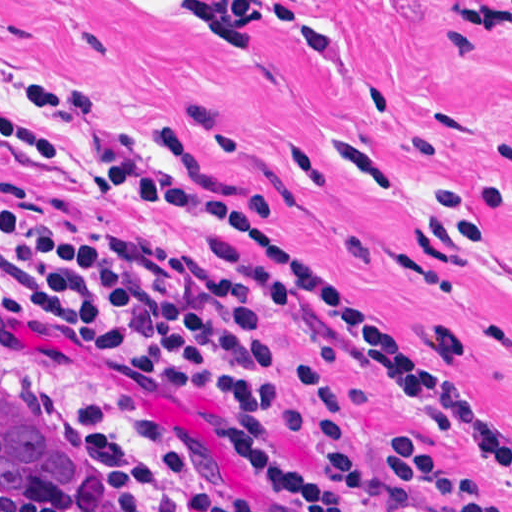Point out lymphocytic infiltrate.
Segmentation results:
<instances>
[{
  "instance_id": "obj_1",
  "label": "lymphocytic infiltrate",
  "mask_w": 512,
  "mask_h": 512,
  "mask_svg": "<svg viewBox=\"0 0 512 512\" xmlns=\"http://www.w3.org/2000/svg\"><path fill=\"white\" fill-rule=\"evenodd\" d=\"M463 28L512 23V0H452ZM0 150H16L15 143ZM109 168L120 186L191 239L245 241L230 266L270 304L321 333L350 341L410 390L420 412L487 456L406 328L291 248L257 234L167 156L78 150ZM14 311L22 340L57 351L81 328L116 373L124 406L161 436L121 374L136 372L173 391L216 402L206 418L215 444L281 494L288 512H346L333 493L277 442L276 431L323 438L341 491L374 512H502L418 436L398 438L385 460L365 455L323 379L295 360L298 411H283L277 359L238 292L189 256L148 236L103 231L14 212ZM0 512H38L0 504ZM166 512H260L229 481L184 475L179 507Z\"/></svg>"
}]
</instances>
